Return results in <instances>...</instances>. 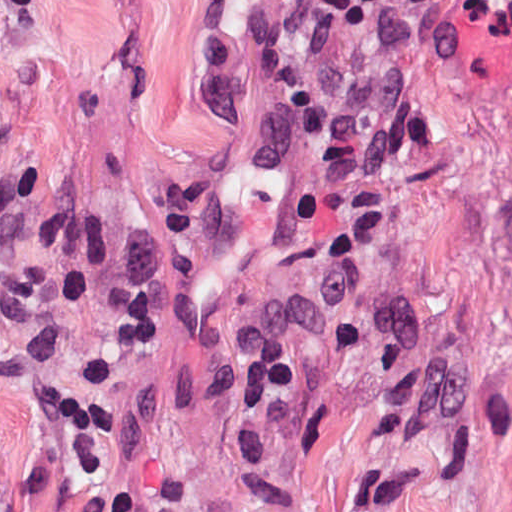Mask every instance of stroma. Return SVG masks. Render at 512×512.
Returning a JSON list of instances; mask_svg holds the SVG:
<instances>
[{"label": "stroma", "mask_w": 512, "mask_h": 512, "mask_svg": "<svg viewBox=\"0 0 512 512\" xmlns=\"http://www.w3.org/2000/svg\"><path fill=\"white\" fill-rule=\"evenodd\" d=\"M0 110L10 165L99 227L144 236L153 191L234 163L204 299L247 330L323 292L347 196L381 193L462 388L453 418L378 434L373 352L341 316L260 481L174 323L128 349L109 311L71 307L72 373L97 350L127 418L124 484L174 470L183 512H512V0H0ZM37 460L0 389V512H33Z\"/></svg>", "instance_id": "35a3bbf8"}]
</instances>
